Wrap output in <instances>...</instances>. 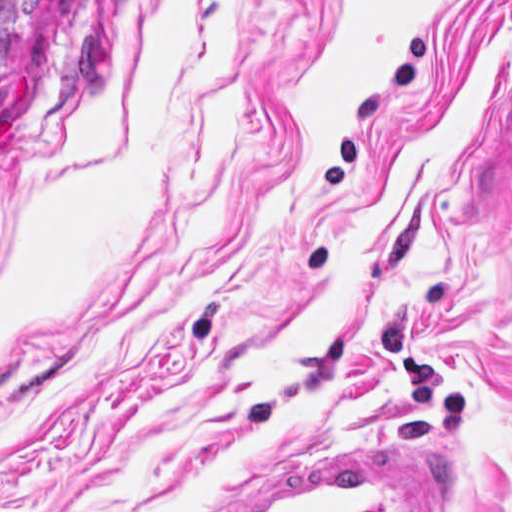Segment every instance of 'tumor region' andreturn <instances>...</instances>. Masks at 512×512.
Listing matches in <instances>:
<instances>
[{
	"label": "tumor region",
	"mask_w": 512,
	"mask_h": 512,
	"mask_svg": "<svg viewBox=\"0 0 512 512\" xmlns=\"http://www.w3.org/2000/svg\"><path fill=\"white\" fill-rule=\"evenodd\" d=\"M46 0H0V121L34 67Z\"/></svg>",
	"instance_id": "tumor-region-1"
}]
</instances>
